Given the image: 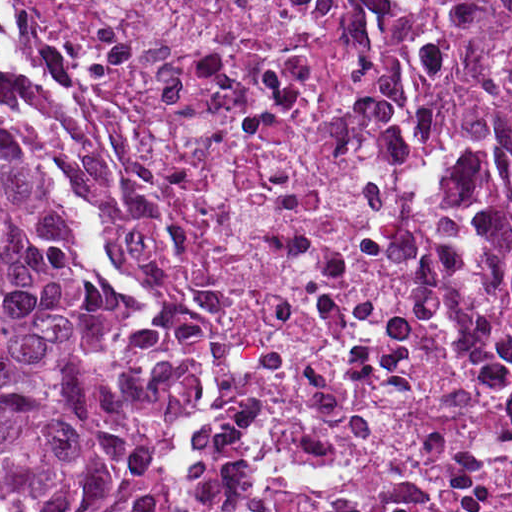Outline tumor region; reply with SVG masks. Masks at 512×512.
<instances>
[{
	"label": "tumor region",
	"mask_w": 512,
	"mask_h": 512,
	"mask_svg": "<svg viewBox=\"0 0 512 512\" xmlns=\"http://www.w3.org/2000/svg\"><path fill=\"white\" fill-rule=\"evenodd\" d=\"M446 21L512 23V0H434ZM148 313L118 303L74 246L66 200L0 126V512H166L160 447L191 399V357L144 353Z\"/></svg>",
	"instance_id": "1"
}]
</instances>
